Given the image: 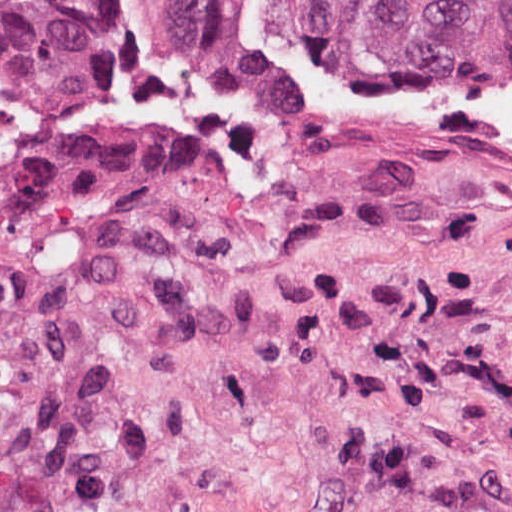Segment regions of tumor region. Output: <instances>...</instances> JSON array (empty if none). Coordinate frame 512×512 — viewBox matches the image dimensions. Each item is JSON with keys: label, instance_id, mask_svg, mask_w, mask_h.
Instances as JSON below:
<instances>
[{"label": "tumor region", "instance_id": "obj_1", "mask_svg": "<svg viewBox=\"0 0 512 512\" xmlns=\"http://www.w3.org/2000/svg\"><path fill=\"white\" fill-rule=\"evenodd\" d=\"M117 0H0V154ZM180 64L279 73L241 0H152ZM277 27L355 73L512 70V0H266Z\"/></svg>", "mask_w": 512, "mask_h": 512}]
</instances>
